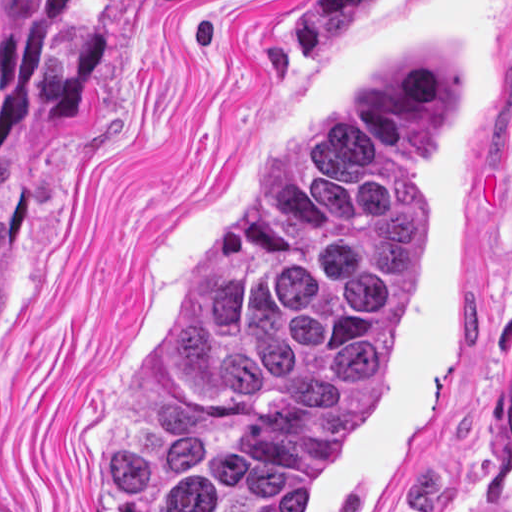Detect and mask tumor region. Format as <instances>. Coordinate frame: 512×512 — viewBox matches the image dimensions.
I'll list each match as a JSON object with an SVG mask.
<instances>
[{
	"label": "tumor region",
	"mask_w": 512,
	"mask_h": 512,
	"mask_svg": "<svg viewBox=\"0 0 512 512\" xmlns=\"http://www.w3.org/2000/svg\"><path fill=\"white\" fill-rule=\"evenodd\" d=\"M387 2L300 0L281 44L336 68ZM467 93L466 46L427 50L293 156L105 409L100 512H303L395 385L439 264L428 176Z\"/></svg>",
	"instance_id": "obj_1"
}]
</instances>
